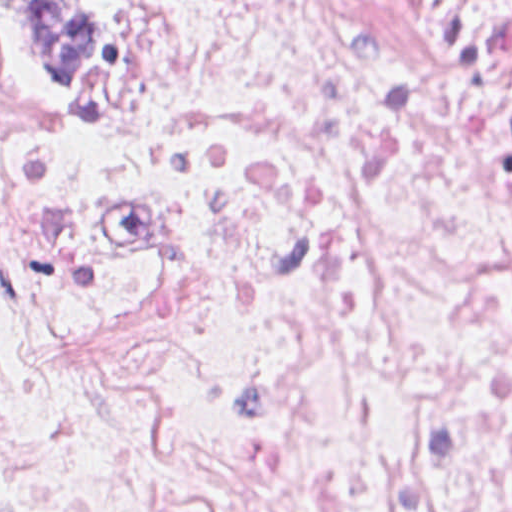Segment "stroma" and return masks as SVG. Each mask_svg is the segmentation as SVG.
<instances>
[{
    "label": "stroma",
    "instance_id": "stroma-1",
    "mask_svg": "<svg viewBox=\"0 0 512 512\" xmlns=\"http://www.w3.org/2000/svg\"><path fill=\"white\" fill-rule=\"evenodd\" d=\"M117 52L118 19L117 35L108 50L91 71L79 75L90 76L89 78L78 82H49L37 75L13 50L10 32L5 19L0 12V55L21 76L41 92L68 104L95 99V96L113 75Z\"/></svg>",
    "mask_w": 512,
    "mask_h": 512
}]
</instances>
